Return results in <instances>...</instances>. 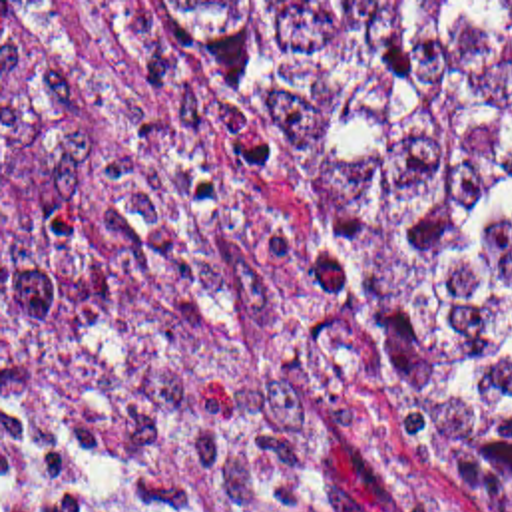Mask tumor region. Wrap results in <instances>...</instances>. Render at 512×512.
I'll return each instance as SVG.
<instances>
[{
    "label": "tumor region",
    "mask_w": 512,
    "mask_h": 512,
    "mask_svg": "<svg viewBox=\"0 0 512 512\" xmlns=\"http://www.w3.org/2000/svg\"><path fill=\"white\" fill-rule=\"evenodd\" d=\"M163 4L327 223L394 410L512 512V2ZM2 412L370 512L295 277L74 2H2Z\"/></svg>",
    "instance_id": "obj_1"
}]
</instances>
